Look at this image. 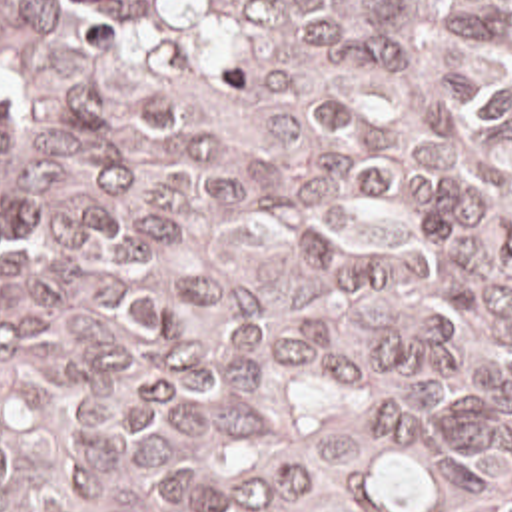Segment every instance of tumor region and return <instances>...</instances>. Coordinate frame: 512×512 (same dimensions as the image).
Returning <instances> with one entry per match:
<instances>
[{
    "label": "tumor region",
    "instance_id": "tumor-region-1",
    "mask_svg": "<svg viewBox=\"0 0 512 512\" xmlns=\"http://www.w3.org/2000/svg\"><path fill=\"white\" fill-rule=\"evenodd\" d=\"M0 512H512V0H0Z\"/></svg>",
    "mask_w": 512,
    "mask_h": 512
}]
</instances>
